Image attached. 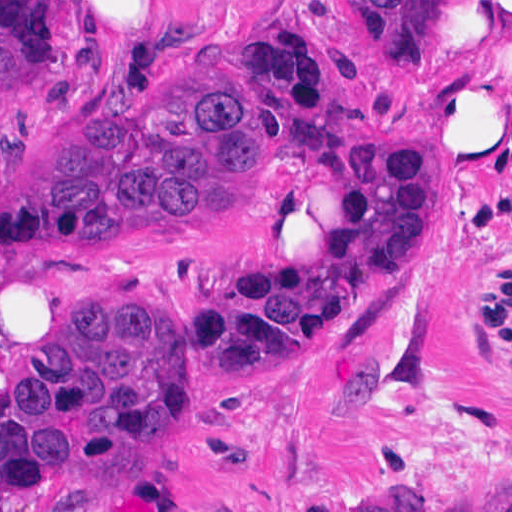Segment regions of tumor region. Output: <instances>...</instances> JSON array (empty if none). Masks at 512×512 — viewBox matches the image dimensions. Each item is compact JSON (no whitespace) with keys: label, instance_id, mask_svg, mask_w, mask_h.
I'll list each match as a JSON object with an SVG mask.
<instances>
[{"label":"tumor region","instance_id":"e687c5a6","mask_svg":"<svg viewBox=\"0 0 512 512\" xmlns=\"http://www.w3.org/2000/svg\"><path fill=\"white\" fill-rule=\"evenodd\" d=\"M465 1L377 4L388 35L433 59ZM236 28L237 66L171 79V99L153 109L100 103L50 158L8 183L0 253L87 252L166 227L231 224L241 192L282 160L319 175L350 210L338 242L325 251L269 245L202 295L212 349L246 382L266 340L426 266L445 234L446 207L422 197L431 139L331 127L285 133L254 80V47ZM55 53L56 0H0V83L28 79ZM187 439L163 296L109 300L63 325L0 403V504L102 460L167 456ZM316 512H428V500L417 487H395Z\"/></svg>","mask_w":512,"mask_h":512}]
</instances>
